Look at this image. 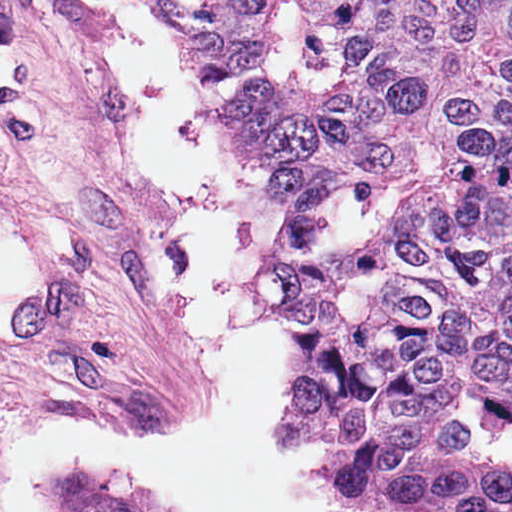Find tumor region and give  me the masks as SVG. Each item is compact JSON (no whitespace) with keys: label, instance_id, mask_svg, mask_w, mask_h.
I'll use <instances>...</instances> for the list:
<instances>
[{"label":"tumor region","instance_id":"obj_1","mask_svg":"<svg viewBox=\"0 0 512 512\" xmlns=\"http://www.w3.org/2000/svg\"><path fill=\"white\" fill-rule=\"evenodd\" d=\"M512 455V0H310Z\"/></svg>","mask_w":512,"mask_h":512}]
</instances>
